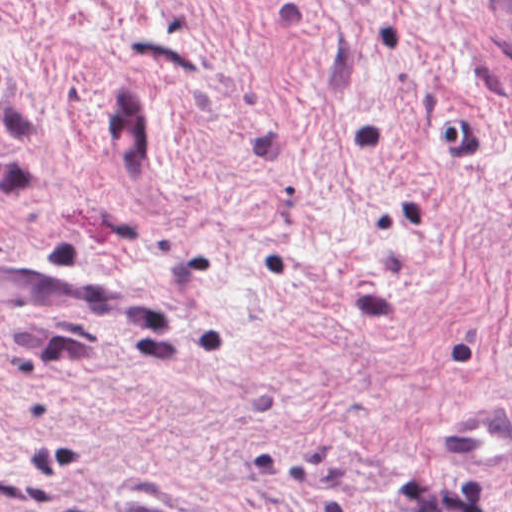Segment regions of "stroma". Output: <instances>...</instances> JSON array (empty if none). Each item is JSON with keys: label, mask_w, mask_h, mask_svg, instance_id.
<instances>
[{"label": "stroma", "mask_w": 512, "mask_h": 512, "mask_svg": "<svg viewBox=\"0 0 512 512\" xmlns=\"http://www.w3.org/2000/svg\"><path fill=\"white\" fill-rule=\"evenodd\" d=\"M489 1L0 0V512H512Z\"/></svg>", "instance_id": "35a3bbf8"}]
</instances>
